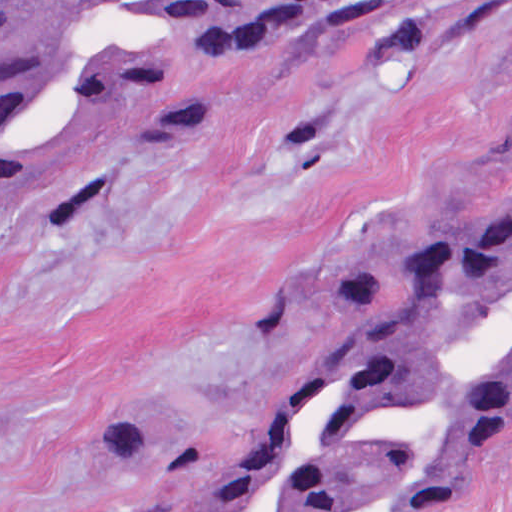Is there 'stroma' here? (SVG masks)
<instances>
[{
  "mask_svg": "<svg viewBox=\"0 0 512 512\" xmlns=\"http://www.w3.org/2000/svg\"><path fill=\"white\" fill-rule=\"evenodd\" d=\"M203 103L36 106L0 188V512H130L119 422L205 463L246 441L338 293L367 290L512 148V0H335L267 49L109 18ZM442 512H512V434Z\"/></svg>",
  "mask_w": 512,
  "mask_h": 512,
  "instance_id": "obj_1",
  "label": "stroma"
}]
</instances>
